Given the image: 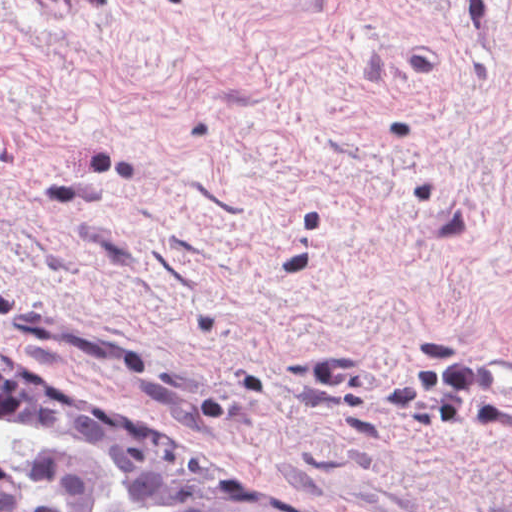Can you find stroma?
<instances>
[{"instance_id": "stroma-1", "label": "stroma", "mask_w": 512, "mask_h": 512, "mask_svg": "<svg viewBox=\"0 0 512 512\" xmlns=\"http://www.w3.org/2000/svg\"><path fill=\"white\" fill-rule=\"evenodd\" d=\"M0 348L267 512H512V0H0Z\"/></svg>"}]
</instances>
